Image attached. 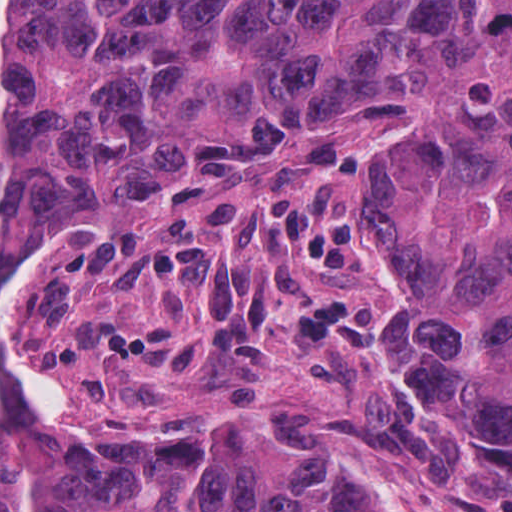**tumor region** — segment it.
Instances as JSON below:
<instances>
[{
    "label": "tumor region",
    "instance_id": "1",
    "mask_svg": "<svg viewBox=\"0 0 512 512\" xmlns=\"http://www.w3.org/2000/svg\"><path fill=\"white\" fill-rule=\"evenodd\" d=\"M490 129L364 291L430 393L512 428V1H0V291L283 127ZM0 512H378L271 459L97 457L0 379Z\"/></svg>",
    "mask_w": 512,
    "mask_h": 512
}]
</instances>
